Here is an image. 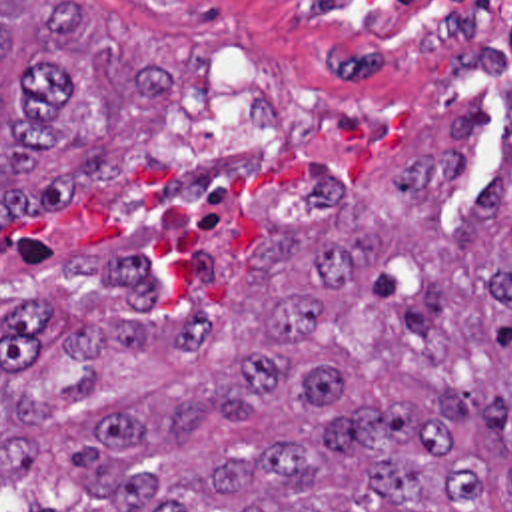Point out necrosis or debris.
Returning a JSON list of instances; mask_svg holds the SVG:
<instances>
[{
  "instance_id": "1",
  "label": "necrosis or debris",
  "mask_w": 512,
  "mask_h": 512,
  "mask_svg": "<svg viewBox=\"0 0 512 512\" xmlns=\"http://www.w3.org/2000/svg\"><path fill=\"white\" fill-rule=\"evenodd\" d=\"M356 13L414 53H481L512 41V0H310Z\"/></svg>"
}]
</instances>
